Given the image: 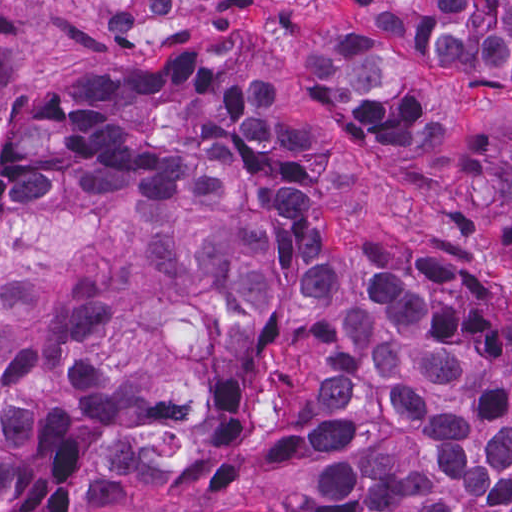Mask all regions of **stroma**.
<instances>
[{"label":"stroma","instance_id":"1","mask_svg":"<svg viewBox=\"0 0 512 512\" xmlns=\"http://www.w3.org/2000/svg\"><path fill=\"white\" fill-rule=\"evenodd\" d=\"M0 1H512V0H0ZM323 198L329 250L345 260H418L485 283L512 305V261L433 217L390 171ZM101 500L32 503L14 512H101Z\"/></svg>","mask_w":512,"mask_h":512}]
</instances>
